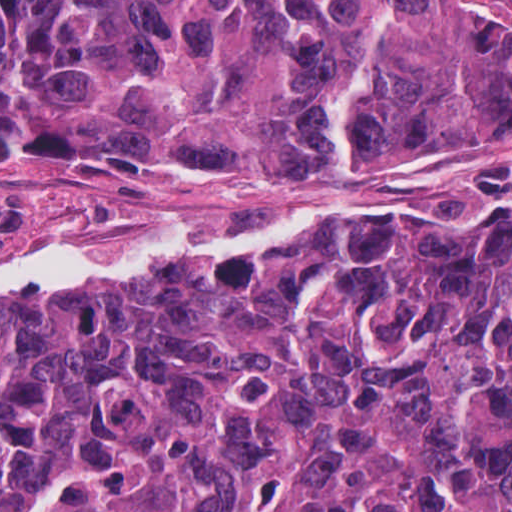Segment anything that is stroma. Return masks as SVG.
<instances>
[{"label":"stroma","mask_w":512,"mask_h":512,"mask_svg":"<svg viewBox=\"0 0 512 512\" xmlns=\"http://www.w3.org/2000/svg\"><path fill=\"white\" fill-rule=\"evenodd\" d=\"M446 2L458 17L478 21L512 0ZM341 164L337 153L319 163L208 176L183 169L148 175L111 164L73 177L4 155L0 258L45 244L91 253L137 225L273 226L327 198ZM412 194L436 217L512 209V111L478 135L364 154V170L339 202L362 211Z\"/></svg>","instance_id":"1"}]
</instances>
